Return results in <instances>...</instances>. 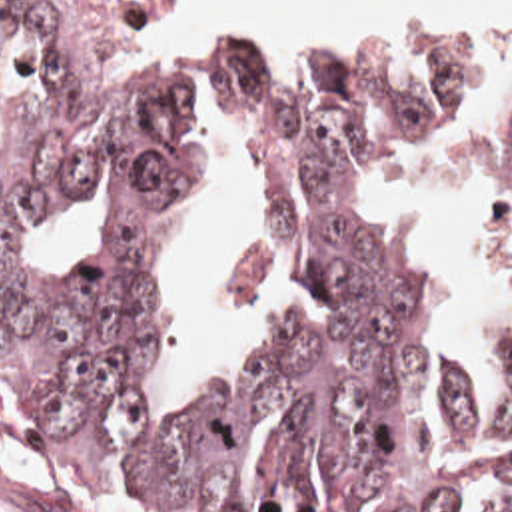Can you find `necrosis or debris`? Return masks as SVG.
I'll list each match as a JSON object with an SVG mask.
<instances>
[{
    "label": "necrosis or debris",
    "instance_id": "1",
    "mask_svg": "<svg viewBox=\"0 0 512 512\" xmlns=\"http://www.w3.org/2000/svg\"><path fill=\"white\" fill-rule=\"evenodd\" d=\"M152 2L154 0H101L111 20L125 26H131L134 22L142 20L152 8Z\"/></svg>",
    "mask_w": 512,
    "mask_h": 512
}]
</instances>
